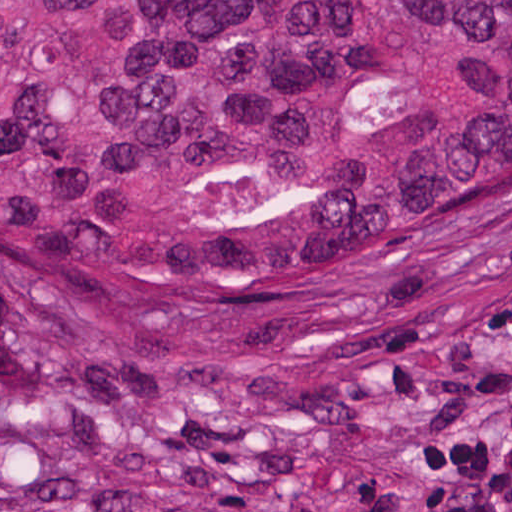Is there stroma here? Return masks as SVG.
Returning <instances> with one entry per match:
<instances>
[{
	"label": "stroma",
	"mask_w": 512,
	"mask_h": 512,
	"mask_svg": "<svg viewBox=\"0 0 512 512\" xmlns=\"http://www.w3.org/2000/svg\"><path fill=\"white\" fill-rule=\"evenodd\" d=\"M0 512H512V222L206 331L0 287Z\"/></svg>",
	"instance_id": "obj_1"
}]
</instances>
